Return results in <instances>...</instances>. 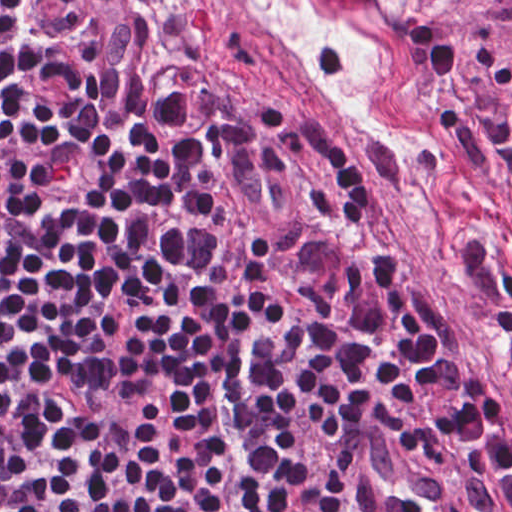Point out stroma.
<instances>
[{
  "instance_id": "obj_1",
  "label": "stroma",
  "mask_w": 512,
  "mask_h": 512,
  "mask_svg": "<svg viewBox=\"0 0 512 512\" xmlns=\"http://www.w3.org/2000/svg\"><path fill=\"white\" fill-rule=\"evenodd\" d=\"M160 92L315 105L493 373L512 353V0H139Z\"/></svg>"
}]
</instances>
